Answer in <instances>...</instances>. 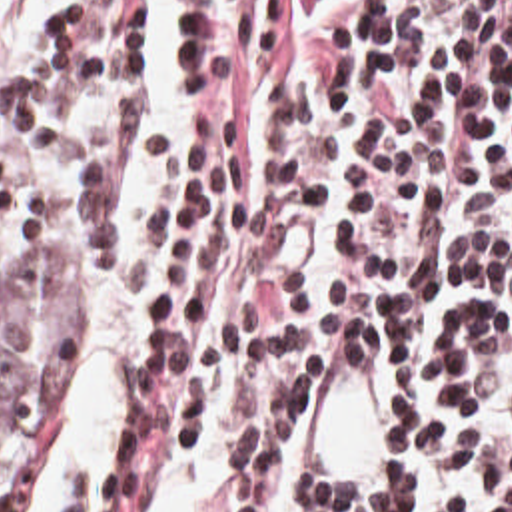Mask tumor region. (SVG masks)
I'll list each match as a JSON object with an SVG mask.
<instances>
[{
    "mask_svg": "<svg viewBox=\"0 0 512 512\" xmlns=\"http://www.w3.org/2000/svg\"><path fill=\"white\" fill-rule=\"evenodd\" d=\"M43 295L0 297V492L23 466L29 430L78 377L68 339Z\"/></svg>",
    "mask_w": 512,
    "mask_h": 512,
    "instance_id": "1",
    "label": "tumor region"
}]
</instances>
